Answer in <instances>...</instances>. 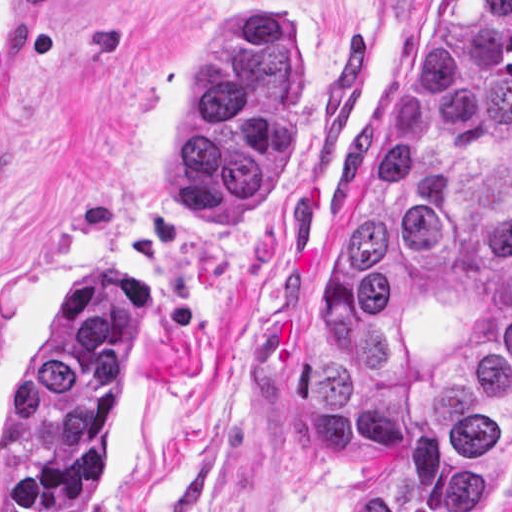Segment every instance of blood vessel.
Here are the masks:
<instances>
[{
  "instance_id": "blood-vessel-1",
  "label": "blood vessel",
  "mask_w": 512,
  "mask_h": 512,
  "mask_svg": "<svg viewBox=\"0 0 512 512\" xmlns=\"http://www.w3.org/2000/svg\"><path fill=\"white\" fill-rule=\"evenodd\" d=\"M44 83V0H0V188L36 131Z\"/></svg>"
}]
</instances>
